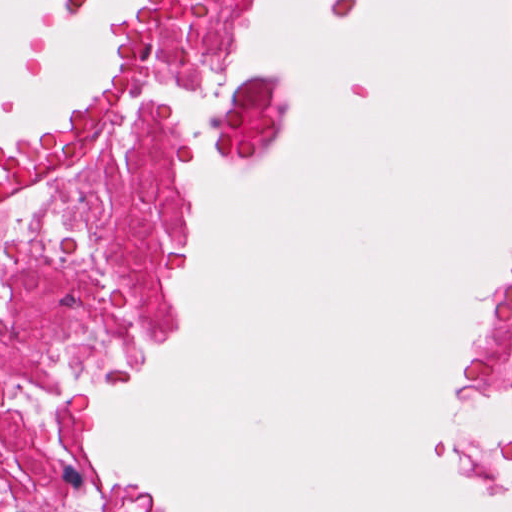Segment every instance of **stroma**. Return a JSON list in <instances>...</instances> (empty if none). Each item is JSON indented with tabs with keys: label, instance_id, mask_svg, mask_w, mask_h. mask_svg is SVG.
<instances>
[{
	"label": "stroma",
	"instance_id": "35a3bbf8",
	"mask_svg": "<svg viewBox=\"0 0 512 512\" xmlns=\"http://www.w3.org/2000/svg\"><path fill=\"white\" fill-rule=\"evenodd\" d=\"M95 0H57L64 23L84 20ZM144 0L104 9V73L84 90L64 93L41 128H20L0 139V159L68 115L93 103L122 77L133 28ZM262 0H223V31L217 51L197 86L214 116L256 123L241 143H199L187 128L167 124L153 138V162L164 182L167 221L153 253L154 316L150 335L121 361L96 373L82 434L75 447V486L89 512H150L116 490L93 459L99 407L177 337V315L168 283L185 280L192 268L195 228L188 197L177 188V168L189 159L218 171L265 166L283 153V116L274 74L258 70L236 98L223 89L234 60L258 23ZM512 288V236L501 262L478 289L476 334L454 354L448 369V401L495 410L510 424L480 440L445 443V458L463 486L485 500L512 508V403L482 374V351Z\"/></svg>",
	"mask_w": 512,
	"mask_h": 512
}]
</instances>
